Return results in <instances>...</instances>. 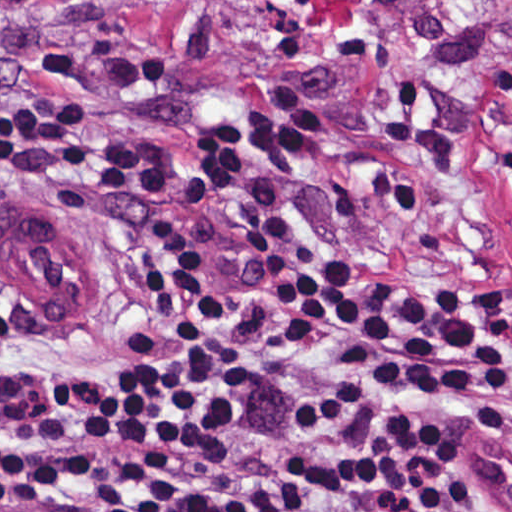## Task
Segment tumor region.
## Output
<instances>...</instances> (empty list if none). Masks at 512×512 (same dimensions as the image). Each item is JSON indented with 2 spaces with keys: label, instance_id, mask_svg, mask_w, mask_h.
Returning <instances> with one entry per match:
<instances>
[{
  "label": "tumor region",
  "instance_id": "e687c5a6",
  "mask_svg": "<svg viewBox=\"0 0 512 512\" xmlns=\"http://www.w3.org/2000/svg\"><path fill=\"white\" fill-rule=\"evenodd\" d=\"M71 0H0V39L42 12Z\"/></svg>",
  "mask_w": 512,
  "mask_h": 512
}]
</instances>
